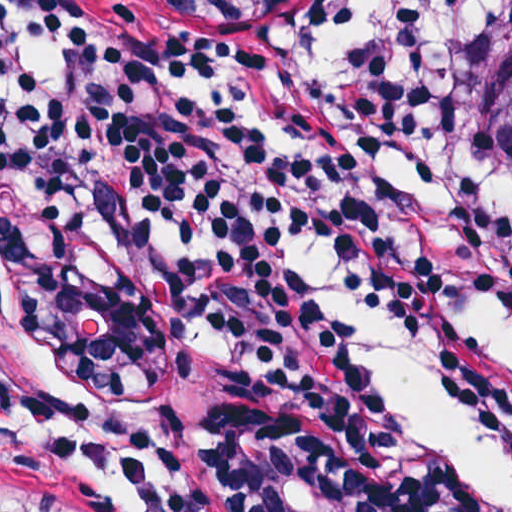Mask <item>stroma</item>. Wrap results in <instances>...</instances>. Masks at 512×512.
<instances>
[{"label":"stroma","mask_w":512,"mask_h":512,"mask_svg":"<svg viewBox=\"0 0 512 512\" xmlns=\"http://www.w3.org/2000/svg\"><path fill=\"white\" fill-rule=\"evenodd\" d=\"M132 1L167 34L171 19L270 27L336 0ZM288 144L374 232L317 153ZM43 366L151 431L176 512H406L392 399L373 419L334 415L311 374L245 320L63 214L0 198V508L124 512L34 434Z\"/></svg>","instance_id":"1"}]
</instances>
